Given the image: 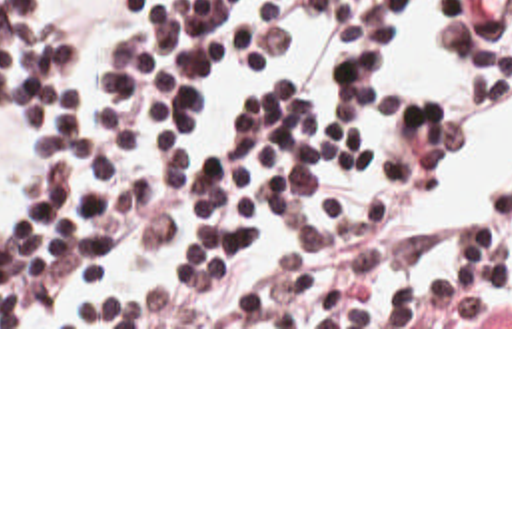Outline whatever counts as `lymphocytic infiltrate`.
I'll list each match as a JSON object with an SVG mask.
<instances>
[{"instance_id": "1", "label": "lymphocytic infiltrate", "mask_w": 512, "mask_h": 512, "mask_svg": "<svg viewBox=\"0 0 512 512\" xmlns=\"http://www.w3.org/2000/svg\"><path fill=\"white\" fill-rule=\"evenodd\" d=\"M336 24V107L276 79L220 145L184 129L212 83L294 46L274 0H124L92 109L62 107L72 34L0 0V99L45 121L47 165L0 243V327H512V191L448 267L404 273L406 233L466 143L442 97L400 115L388 175L372 111L418 0H310ZM470 99L512 103V0H444Z\"/></svg>"}]
</instances>
